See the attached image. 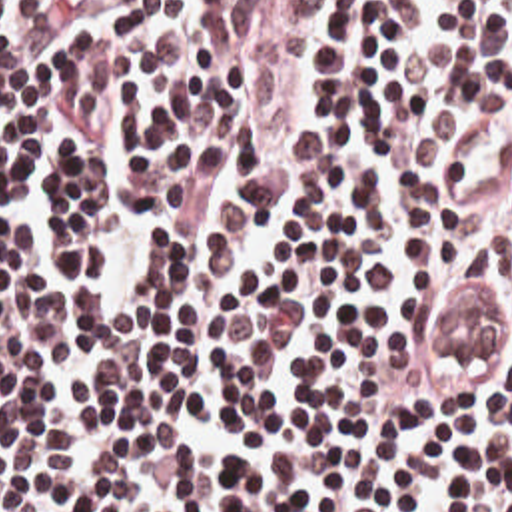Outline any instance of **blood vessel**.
<instances>
[{"instance_id":"blood-vessel-1","label":"blood vessel","mask_w":512,"mask_h":512,"mask_svg":"<svg viewBox=\"0 0 512 512\" xmlns=\"http://www.w3.org/2000/svg\"><path fill=\"white\" fill-rule=\"evenodd\" d=\"M472 286L448 284L432 304L430 354L440 360H490L502 346V310Z\"/></svg>"}]
</instances>
